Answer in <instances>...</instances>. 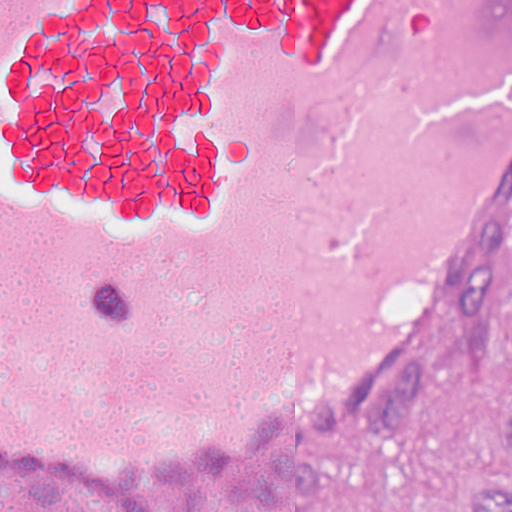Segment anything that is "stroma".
<instances>
[{"label": "stroma", "instance_id": "1", "mask_svg": "<svg viewBox=\"0 0 512 512\" xmlns=\"http://www.w3.org/2000/svg\"><path fill=\"white\" fill-rule=\"evenodd\" d=\"M512 170L346 424L310 447L146 495L89 497L0 463V512H477L512 469Z\"/></svg>", "mask_w": 512, "mask_h": 512}]
</instances>
